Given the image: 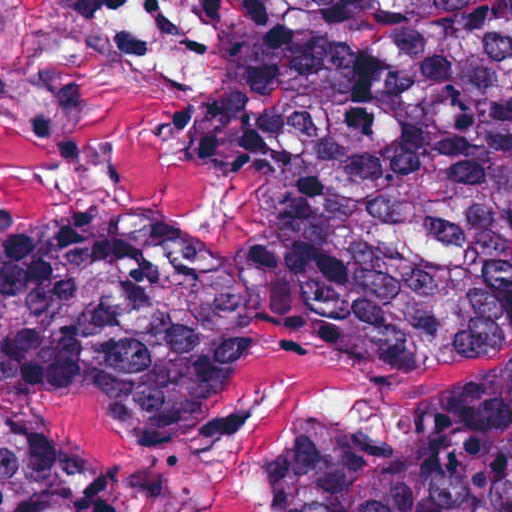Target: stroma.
Here are the masks:
<instances>
[{
    "mask_svg": "<svg viewBox=\"0 0 512 512\" xmlns=\"http://www.w3.org/2000/svg\"><path fill=\"white\" fill-rule=\"evenodd\" d=\"M280 146L239 91V0H0V236L145 226L241 250L263 234ZM445 346L493 347L441 366ZM501 356L512 299L388 343L376 362L277 351L191 438L65 401L54 427L104 448L56 449L118 475L135 512H281L273 459L292 422L391 442L427 394Z\"/></svg>",
    "mask_w": 512,
    "mask_h": 512,
    "instance_id": "35a3bbf8",
    "label": "stroma"
}]
</instances>
